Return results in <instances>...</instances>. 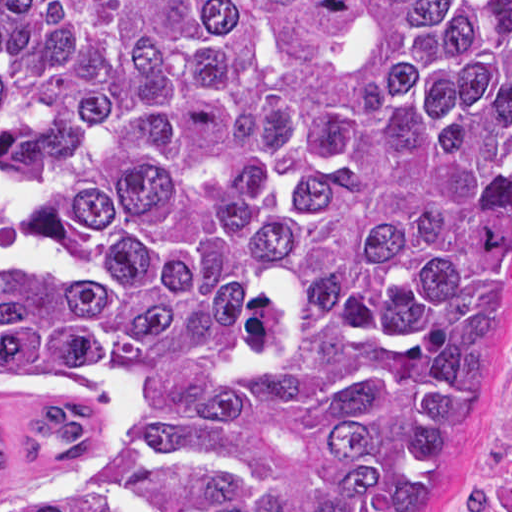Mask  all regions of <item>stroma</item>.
Masks as SVG:
<instances>
[{
	"mask_svg": "<svg viewBox=\"0 0 512 512\" xmlns=\"http://www.w3.org/2000/svg\"><path fill=\"white\" fill-rule=\"evenodd\" d=\"M436 512H512V378L451 497Z\"/></svg>",
	"mask_w": 512,
	"mask_h": 512,
	"instance_id": "obj_1",
	"label": "stroma"
}]
</instances>
